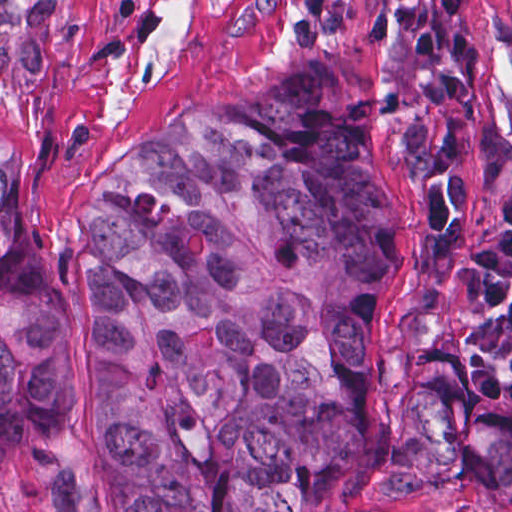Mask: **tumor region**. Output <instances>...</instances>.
Wrapping results in <instances>:
<instances>
[{"mask_svg":"<svg viewBox=\"0 0 512 512\" xmlns=\"http://www.w3.org/2000/svg\"><path fill=\"white\" fill-rule=\"evenodd\" d=\"M478 58L476 0L395 4L416 269L391 416L368 350L399 222L375 178L382 115L341 73L213 101L85 193V448L123 512H360L353 483L456 474L512 502V135L478 111L465 144ZM70 342L0 144V467L56 429Z\"/></svg>","mask_w":512,"mask_h":512,"instance_id":"1","label":"tumor region"}]
</instances>
